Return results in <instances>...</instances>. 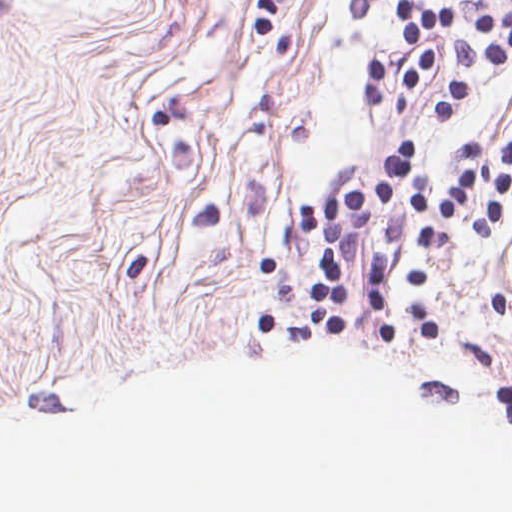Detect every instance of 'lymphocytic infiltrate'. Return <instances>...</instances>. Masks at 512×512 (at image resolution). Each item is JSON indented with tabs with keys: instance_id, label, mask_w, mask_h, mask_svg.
<instances>
[{
	"instance_id": "1",
	"label": "lymphocytic infiltrate",
	"mask_w": 512,
	"mask_h": 512,
	"mask_svg": "<svg viewBox=\"0 0 512 512\" xmlns=\"http://www.w3.org/2000/svg\"><path fill=\"white\" fill-rule=\"evenodd\" d=\"M390 9L405 34V61L392 118L412 110L429 79L434 37L451 42L457 61L433 113L438 120L452 118L474 61L504 63L512 55L510 16L488 12L462 32L458 12L449 8H421L412 6L410 0H394ZM417 151L408 140H396L382 160L379 183L310 200L292 214L297 231L326 242L324 266L315 276L343 285L347 257L364 248L368 293L389 299L393 251L371 229L378 214L389 241L400 246L404 222L399 202L408 201L418 222L417 240L427 246L440 218L460 220L480 235L496 230L512 195V133L505 155L496 160L486 158L480 138L451 146V183L443 193L434 194L429 173L417 166Z\"/></svg>"
}]
</instances>
